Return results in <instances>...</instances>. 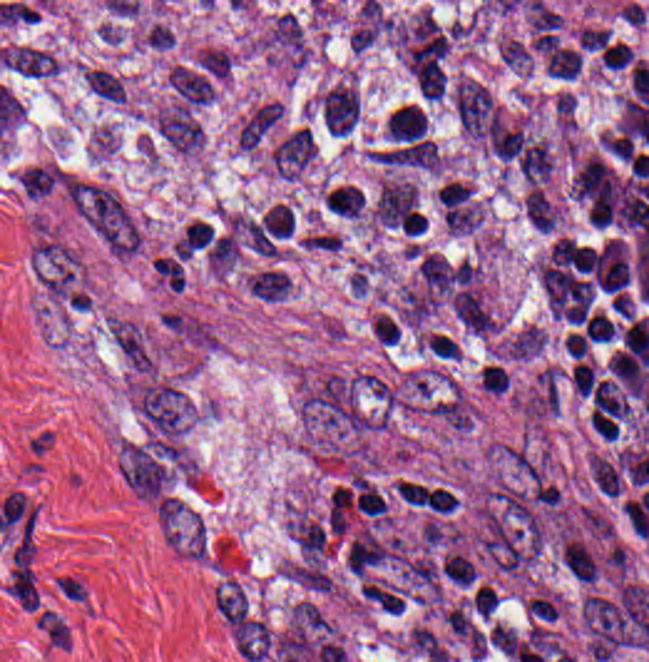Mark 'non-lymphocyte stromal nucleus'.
<instances>
[{
  "instance_id": "1",
  "label": "non-lymphocyte stromal nucleus",
  "mask_w": 649,
  "mask_h": 662,
  "mask_svg": "<svg viewBox=\"0 0 649 662\" xmlns=\"http://www.w3.org/2000/svg\"><path fill=\"white\" fill-rule=\"evenodd\" d=\"M63 200L108 254L129 259L135 253L142 225L117 189L92 176H66Z\"/></svg>"
}]
</instances>
